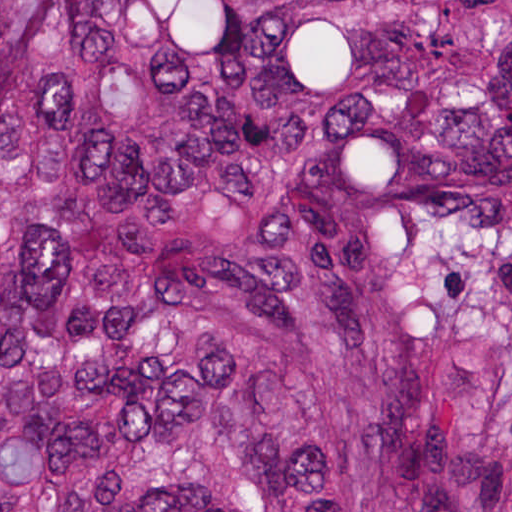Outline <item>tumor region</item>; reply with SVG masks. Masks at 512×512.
<instances>
[{"label":"tumor region","mask_w":512,"mask_h":512,"mask_svg":"<svg viewBox=\"0 0 512 512\" xmlns=\"http://www.w3.org/2000/svg\"><path fill=\"white\" fill-rule=\"evenodd\" d=\"M0 512H512V0H0Z\"/></svg>","instance_id":"1"}]
</instances>
